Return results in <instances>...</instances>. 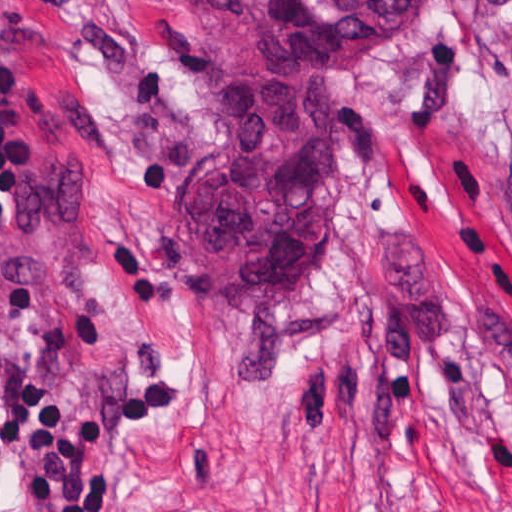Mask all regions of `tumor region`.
<instances>
[{
	"label": "tumor region",
	"mask_w": 512,
	"mask_h": 512,
	"mask_svg": "<svg viewBox=\"0 0 512 512\" xmlns=\"http://www.w3.org/2000/svg\"><path fill=\"white\" fill-rule=\"evenodd\" d=\"M423 0H186L217 121L173 221L216 300H268L326 269L358 53Z\"/></svg>",
	"instance_id": "tumor-region-1"
}]
</instances>
